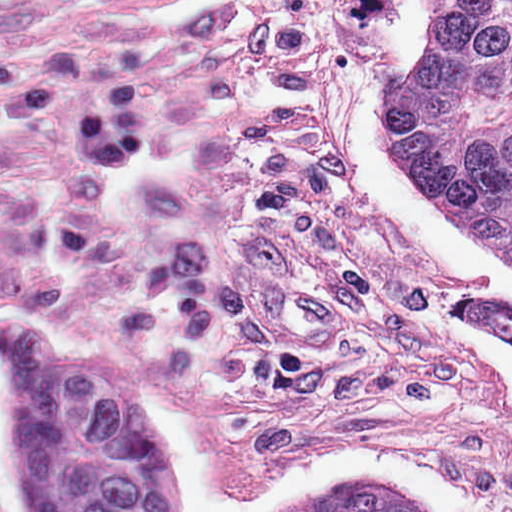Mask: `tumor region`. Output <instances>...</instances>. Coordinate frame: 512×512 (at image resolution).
<instances>
[{"mask_svg": "<svg viewBox=\"0 0 512 512\" xmlns=\"http://www.w3.org/2000/svg\"><path fill=\"white\" fill-rule=\"evenodd\" d=\"M432 41L389 72V118L423 191L512 261V0H428ZM444 217V215H443ZM461 323L512 340V292L457 303Z\"/></svg>", "mask_w": 512, "mask_h": 512, "instance_id": "e687c5a6", "label": "tumor region"}]
</instances>
